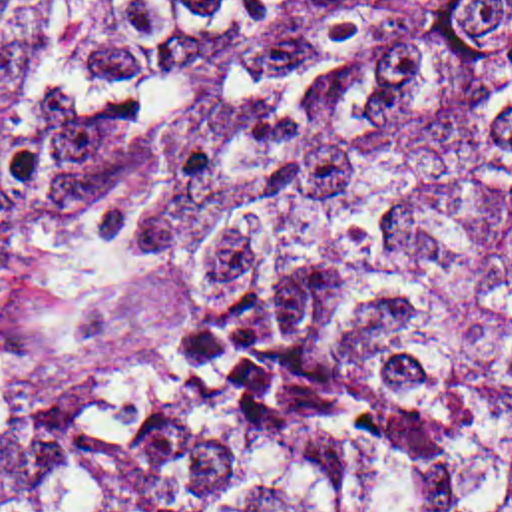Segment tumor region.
Wrapping results in <instances>:
<instances>
[{
  "mask_svg": "<svg viewBox=\"0 0 512 512\" xmlns=\"http://www.w3.org/2000/svg\"><path fill=\"white\" fill-rule=\"evenodd\" d=\"M0 512H512V0H0Z\"/></svg>",
  "mask_w": 512,
  "mask_h": 512,
  "instance_id": "1",
  "label": "tumor region"
}]
</instances>
